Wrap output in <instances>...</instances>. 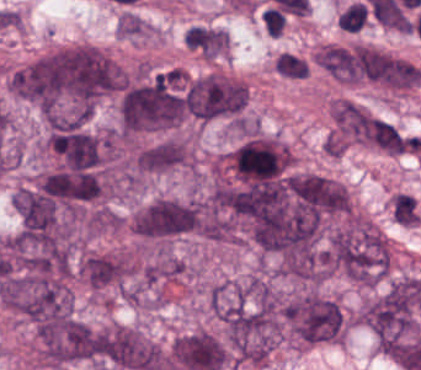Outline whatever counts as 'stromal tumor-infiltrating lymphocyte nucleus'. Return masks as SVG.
I'll list each match as a JSON object with an SVG mask.
<instances>
[{
    "label": "stromal tumor-infiltrating lymphocyte nucleus",
    "instance_id": "bc302bb0",
    "mask_svg": "<svg viewBox=\"0 0 421 370\" xmlns=\"http://www.w3.org/2000/svg\"><path fill=\"white\" fill-rule=\"evenodd\" d=\"M369 17L366 6L360 0H353L341 10L337 24L347 32H358Z\"/></svg>",
    "mask_w": 421,
    "mask_h": 370
},
{
    "label": "stromal tumor-infiltrating lymphocyte nucleus",
    "instance_id": "52c7bb5b",
    "mask_svg": "<svg viewBox=\"0 0 421 370\" xmlns=\"http://www.w3.org/2000/svg\"><path fill=\"white\" fill-rule=\"evenodd\" d=\"M263 27L269 35L282 36L289 18L278 11H270L261 17Z\"/></svg>",
    "mask_w": 421,
    "mask_h": 370
}]
</instances>
